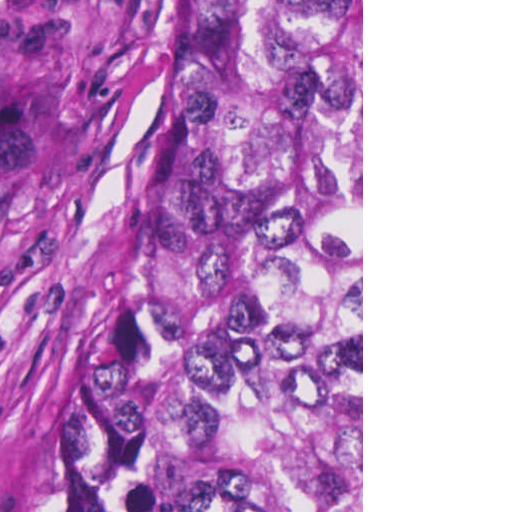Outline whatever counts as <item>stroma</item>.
Here are the masks:
<instances>
[{"label": "stroma", "mask_w": 512, "mask_h": 512, "mask_svg": "<svg viewBox=\"0 0 512 512\" xmlns=\"http://www.w3.org/2000/svg\"><path fill=\"white\" fill-rule=\"evenodd\" d=\"M184 64L185 0H0V512L113 305Z\"/></svg>", "instance_id": "stroma-1"}]
</instances>
